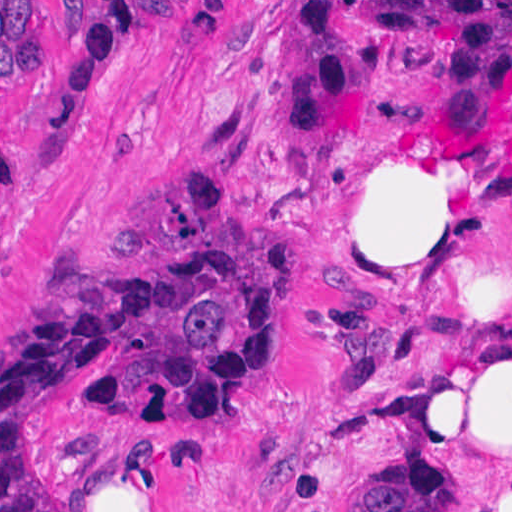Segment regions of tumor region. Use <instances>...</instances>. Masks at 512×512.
I'll return each mask as SVG.
<instances>
[{
	"instance_id": "obj_1",
	"label": "tumor region",
	"mask_w": 512,
	"mask_h": 512,
	"mask_svg": "<svg viewBox=\"0 0 512 512\" xmlns=\"http://www.w3.org/2000/svg\"><path fill=\"white\" fill-rule=\"evenodd\" d=\"M272 328V290L241 245L161 246L46 298L0 364V512H56L28 452L31 417L77 371L109 366L106 406L157 414L240 375ZM377 512H466L448 457L385 463Z\"/></svg>"
}]
</instances>
